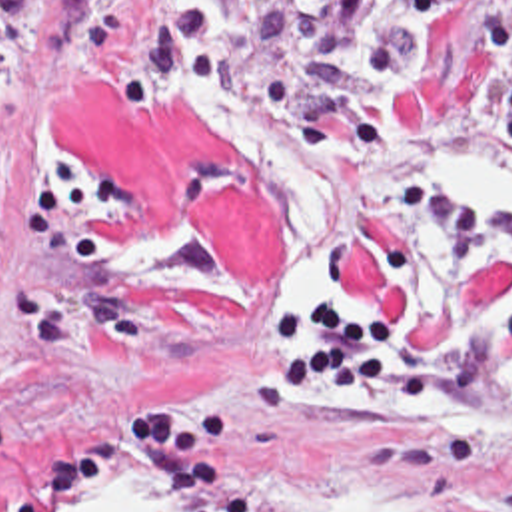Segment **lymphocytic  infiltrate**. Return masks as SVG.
Listing matches in <instances>:
<instances>
[{"mask_svg": "<svg viewBox=\"0 0 512 512\" xmlns=\"http://www.w3.org/2000/svg\"><path fill=\"white\" fill-rule=\"evenodd\" d=\"M465 0H329L337 21L363 45L367 71L347 89H329L323 41L295 53L293 103L281 121L325 137L391 143L393 101L423 63L427 37L439 11ZM39 0H0V75L13 73L31 43Z\"/></svg>", "mask_w": 512, "mask_h": 512, "instance_id": "lymphocytic-infiltrate-1", "label": "lymphocytic infiltrate"}]
</instances>
